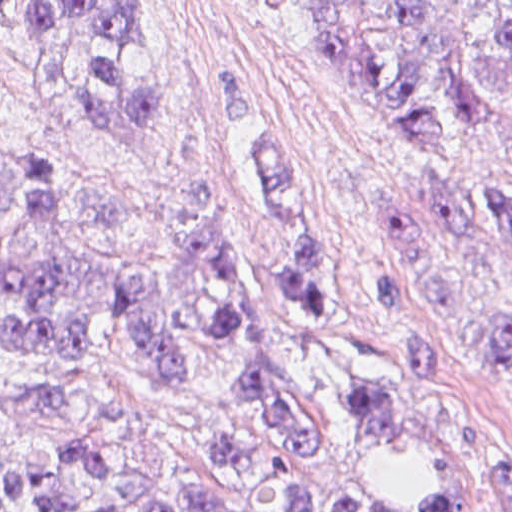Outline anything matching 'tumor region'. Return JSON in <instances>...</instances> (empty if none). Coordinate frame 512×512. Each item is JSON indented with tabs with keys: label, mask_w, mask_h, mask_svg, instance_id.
<instances>
[{
	"label": "tumor region",
	"mask_w": 512,
	"mask_h": 512,
	"mask_svg": "<svg viewBox=\"0 0 512 512\" xmlns=\"http://www.w3.org/2000/svg\"><path fill=\"white\" fill-rule=\"evenodd\" d=\"M256 1L299 13L317 51L354 76L400 140L431 158L421 148L467 151L512 122V0ZM0 15L18 28L34 61L71 88L95 128L148 135L166 121L153 84L129 72L131 50L145 42L138 0H0ZM255 108L230 126L227 141ZM252 156L290 232L277 279L330 345L353 425L416 447L433 467L426 496L405 512H466L456 469L363 372L307 237L295 160L274 140L257 141ZM155 205L175 247L128 258L87 237L35 151L17 146L0 157V350L37 369L17 401L30 415L79 405L74 369L97 324L125 326L164 387L187 386L200 356H215L230 374L226 398L242 421L206 450L222 482L171 488L64 444L35 458L0 457V512H319L315 493L291 468L297 452L315 451L316 431L276 361L229 208L219 193L202 205ZM390 226L417 286L512 371V290L503 268L512 249V187H502L482 215L410 177L395 185ZM371 261L403 366L435 373L438 351L404 321L397 275ZM491 488L500 511L512 512V470L496 468ZM334 512L397 511L337 503Z\"/></svg>",
	"instance_id": "e687c5a6"
}]
</instances>
